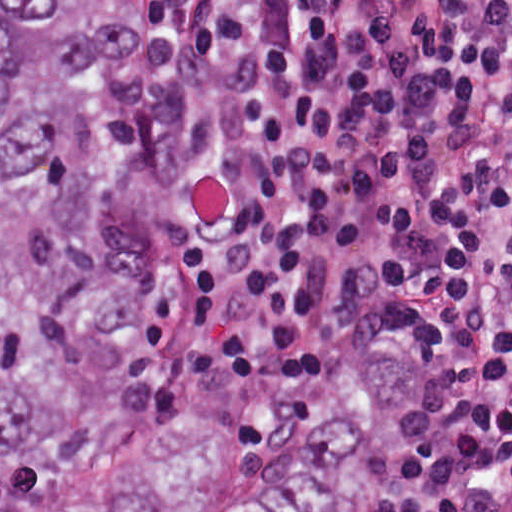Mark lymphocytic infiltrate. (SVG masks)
Instances as JSON below:
<instances>
[{
  "label": "lymphocytic infiltrate",
  "instance_id": "1",
  "mask_svg": "<svg viewBox=\"0 0 512 512\" xmlns=\"http://www.w3.org/2000/svg\"><path fill=\"white\" fill-rule=\"evenodd\" d=\"M184 352L230 419L415 396L418 512H512V0H165Z\"/></svg>",
  "mask_w": 512,
  "mask_h": 512
}]
</instances>
